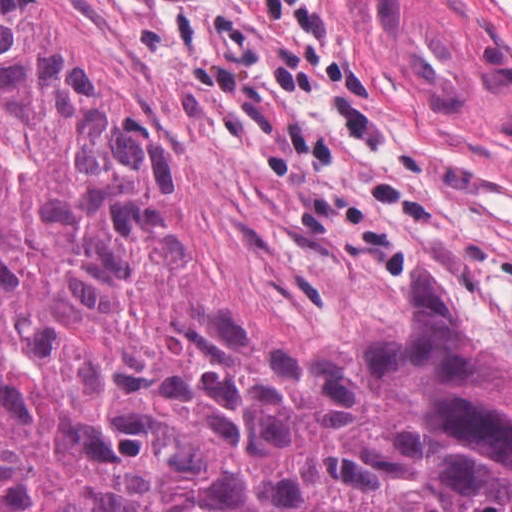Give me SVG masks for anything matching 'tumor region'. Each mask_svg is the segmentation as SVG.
<instances>
[{"instance_id": "tumor-region-1", "label": "tumor region", "mask_w": 512, "mask_h": 512, "mask_svg": "<svg viewBox=\"0 0 512 512\" xmlns=\"http://www.w3.org/2000/svg\"><path fill=\"white\" fill-rule=\"evenodd\" d=\"M175 163L0 0V512H512V362L426 257L407 323L271 351L164 308Z\"/></svg>"}]
</instances>
